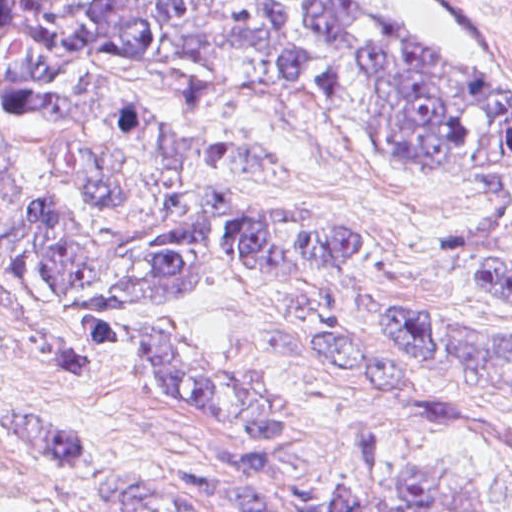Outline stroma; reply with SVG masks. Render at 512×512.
Returning a JSON list of instances; mask_svg holds the SVG:
<instances>
[{
	"instance_id": "stroma-1",
	"label": "stroma",
	"mask_w": 512,
	"mask_h": 512,
	"mask_svg": "<svg viewBox=\"0 0 512 512\" xmlns=\"http://www.w3.org/2000/svg\"><path fill=\"white\" fill-rule=\"evenodd\" d=\"M440 48L512 80V0H355ZM253 133L289 161L317 202L358 225L402 260H366L336 312L357 345L404 362L429 392L468 407V418L393 444L404 464H430L479 486L476 512H512V389L460 385L388 330L400 312L453 318L512 340V310L471 291L444 261L483 247L485 199L433 166L385 148L363 122L293 87H249ZM142 323L222 350L264 376L285 416L271 495L291 508L293 485L340 461L351 396L306 356L300 303L248 279L203 276L167 306L135 311ZM0 414L71 428L143 468L221 476L210 432L183 404L146 383L86 362L0 321ZM0 512H230L152 479L77 469L0 448ZM317 512H324L322 503Z\"/></svg>"
}]
</instances>
